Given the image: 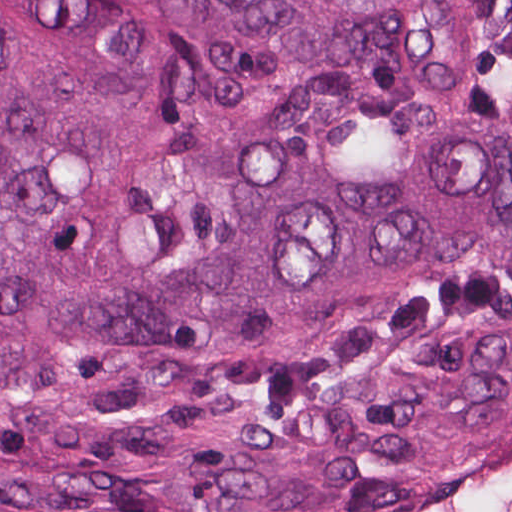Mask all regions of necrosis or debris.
<instances>
[{
    "mask_svg": "<svg viewBox=\"0 0 512 512\" xmlns=\"http://www.w3.org/2000/svg\"><path fill=\"white\" fill-rule=\"evenodd\" d=\"M353 512H512V423L420 486Z\"/></svg>",
    "mask_w": 512,
    "mask_h": 512,
    "instance_id": "obj_1",
    "label": "necrosis or debris"
}]
</instances>
